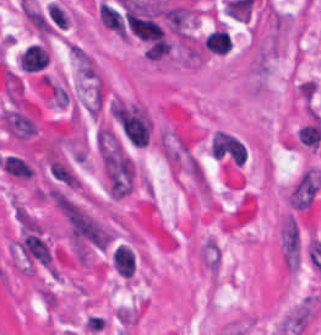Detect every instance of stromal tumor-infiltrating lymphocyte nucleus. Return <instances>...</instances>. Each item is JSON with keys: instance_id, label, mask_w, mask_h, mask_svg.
<instances>
[{"instance_id": "obj_1", "label": "stromal tumor-infiltrating lymphocyte nucleus", "mask_w": 321, "mask_h": 335, "mask_svg": "<svg viewBox=\"0 0 321 335\" xmlns=\"http://www.w3.org/2000/svg\"><path fill=\"white\" fill-rule=\"evenodd\" d=\"M49 64V49L42 41H35L24 48L18 56L20 73L42 75Z\"/></svg>"}, {"instance_id": "obj_2", "label": "stromal tumor-infiltrating lymphocyte nucleus", "mask_w": 321, "mask_h": 335, "mask_svg": "<svg viewBox=\"0 0 321 335\" xmlns=\"http://www.w3.org/2000/svg\"><path fill=\"white\" fill-rule=\"evenodd\" d=\"M113 268L118 275L131 277L135 270L132 247L117 245L112 252Z\"/></svg>"}, {"instance_id": "obj_3", "label": "stromal tumor-infiltrating lymphocyte nucleus", "mask_w": 321, "mask_h": 335, "mask_svg": "<svg viewBox=\"0 0 321 335\" xmlns=\"http://www.w3.org/2000/svg\"><path fill=\"white\" fill-rule=\"evenodd\" d=\"M205 47L215 54H226L232 47L231 37L222 25L212 30L204 39Z\"/></svg>"}, {"instance_id": "obj_4", "label": "stromal tumor-infiltrating lymphocyte nucleus", "mask_w": 321, "mask_h": 335, "mask_svg": "<svg viewBox=\"0 0 321 335\" xmlns=\"http://www.w3.org/2000/svg\"><path fill=\"white\" fill-rule=\"evenodd\" d=\"M3 171L15 180H28L32 172L27 160L13 155H5L2 160Z\"/></svg>"}]
</instances>
